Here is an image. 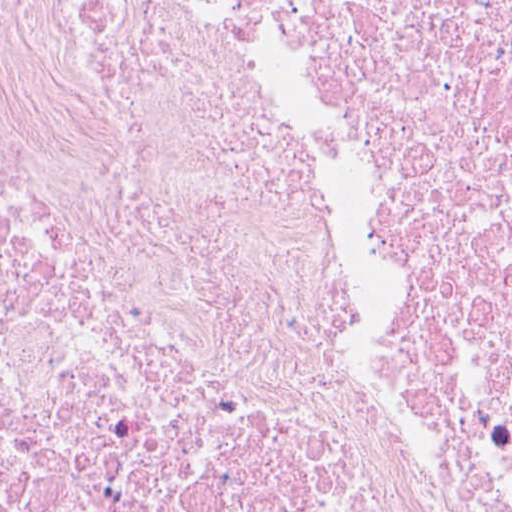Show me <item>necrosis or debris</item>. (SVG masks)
<instances>
[{"label":"necrosis or debris","mask_w":512,"mask_h":512,"mask_svg":"<svg viewBox=\"0 0 512 512\" xmlns=\"http://www.w3.org/2000/svg\"><path fill=\"white\" fill-rule=\"evenodd\" d=\"M0 512H512V0H0Z\"/></svg>","instance_id":"1"}]
</instances>
